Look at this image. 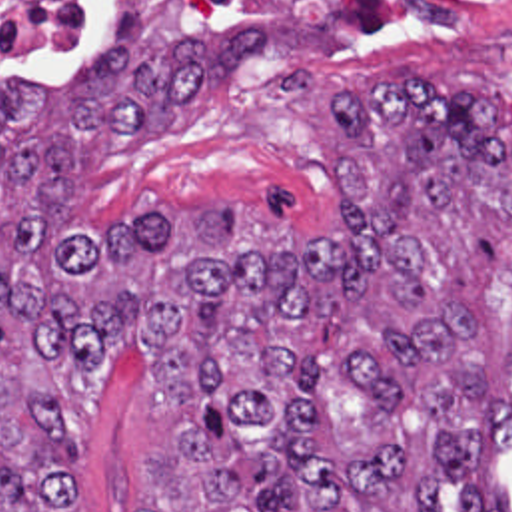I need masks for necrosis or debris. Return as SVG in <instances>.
Listing matches in <instances>:
<instances>
[{
    "mask_svg": "<svg viewBox=\"0 0 512 512\" xmlns=\"http://www.w3.org/2000/svg\"><path fill=\"white\" fill-rule=\"evenodd\" d=\"M103 0H0V41L65 35ZM271 33L397 39L441 31L512 33V0H221Z\"/></svg>",
    "mask_w": 512,
    "mask_h": 512,
    "instance_id": "obj_1",
    "label": "necrosis or debris"
}]
</instances>
